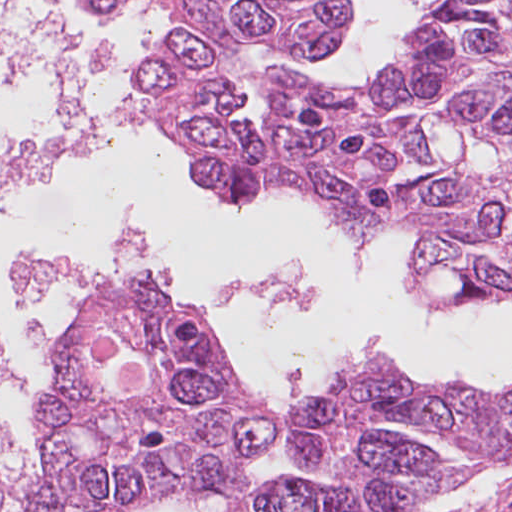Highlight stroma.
Here are the masks:
<instances>
[{
    "instance_id": "1",
    "label": "stroma",
    "mask_w": 512,
    "mask_h": 512,
    "mask_svg": "<svg viewBox=\"0 0 512 512\" xmlns=\"http://www.w3.org/2000/svg\"><path fill=\"white\" fill-rule=\"evenodd\" d=\"M158 3V0H156ZM159 5V4H158ZM160 16L162 20V30L163 33L165 29L171 27L173 24L179 22L177 18L167 15L160 8ZM420 16L413 24L412 28L419 21ZM348 32L345 34L341 44L335 50L334 53H339L342 51L346 37ZM406 41V37L404 38L403 43L396 50L391 60L396 58L402 51H404V43ZM226 44L227 48V69L235 76L234 72L228 68V61L230 59L229 56V47L235 42L242 43V41H220ZM252 84L261 92L265 99V91H263L260 87H258L255 83ZM146 92L139 101L148 109L149 107L146 104ZM150 110V109H149ZM236 124L241 125L238 116L236 115L234 120ZM262 135H265L263 133ZM187 153V152H186ZM188 161L190 164V157L187 153ZM346 229V228H345ZM347 230V229H346ZM348 231V230H347ZM349 232V231H348ZM352 236L353 234L349 232ZM404 236L409 240L412 246V251H414L416 246V238L414 235L410 233H403ZM354 237V236H353ZM355 238V237H354ZM356 239V238H355ZM384 239V238H383ZM382 239V241H383ZM380 244L376 247L375 250L378 249ZM374 250V251H375ZM133 284H158L155 282L149 281H140ZM160 285V284H158ZM165 291L173 296L181 309L185 312V314L189 317L192 325L206 342L214 364L217 366L219 371L231 385L236 394H238L245 402L248 409L262 417L263 419L273 423L279 429L278 425L280 419L277 418L265 405L261 395L258 392L256 385L253 381L248 377L245 371L239 367L234 360L231 358L228 349L223 343L222 339L219 335L214 332L207 320L201 317L198 312L194 309L193 305L186 299L180 298L172 293H170L165 287L161 286ZM472 308L479 309H487L494 310L500 308H512V300L509 302H494V303H485L479 306H468ZM63 338V337H62ZM62 338L60 340V344L58 347L56 358L52 364V367L48 373L47 379V387L46 393L43 399L42 407H41V420H40V440L42 445L44 428L46 424V420L48 417V413L50 410L53 394H54V379L56 374V369L59 360L60 346L62 342ZM408 371V370H407ZM409 372V371H408ZM410 373V372H409ZM411 374V373H410ZM411 376L419 381L422 384H425L420 379ZM426 385V384H425ZM474 389V388H473ZM477 392L483 394H489L485 392L478 391ZM41 467V452H40V460L39 466ZM36 487H37V477L35 481L34 487V495L33 501L29 508L28 512H32L35 501H36ZM411 512H512V461L506 462L500 465L493 466L488 468L476 476H474L469 482H466L458 487H455L438 497L430 500L429 502L421 505L420 507L412 510Z\"/></svg>"
}]
</instances>
